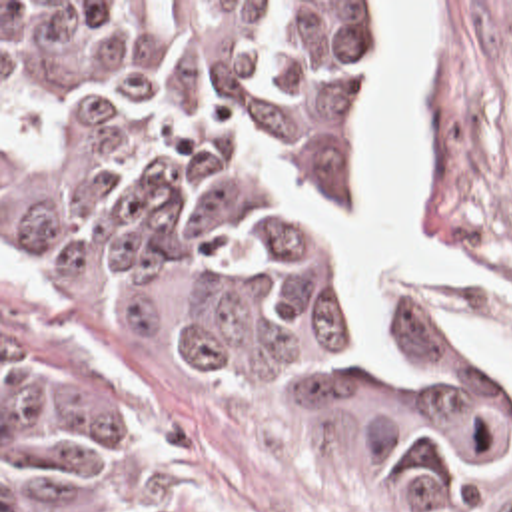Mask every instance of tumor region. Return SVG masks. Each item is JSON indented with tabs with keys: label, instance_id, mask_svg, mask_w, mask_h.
I'll return each instance as SVG.
<instances>
[{
	"label": "tumor region",
	"instance_id": "obj_1",
	"mask_svg": "<svg viewBox=\"0 0 512 512\" xmlns=\"http://www.w3.org/2000/svg\"><path fill=\"white\" fill-rule=\"evenodd\" d=\"M373 2H2V512H120L124 457L66 311L335 417L512 512V381L377 335L325 270Z\"/></svg>",
	"mask_w": 512,
	"mask_h": 512
}]
</instances>
